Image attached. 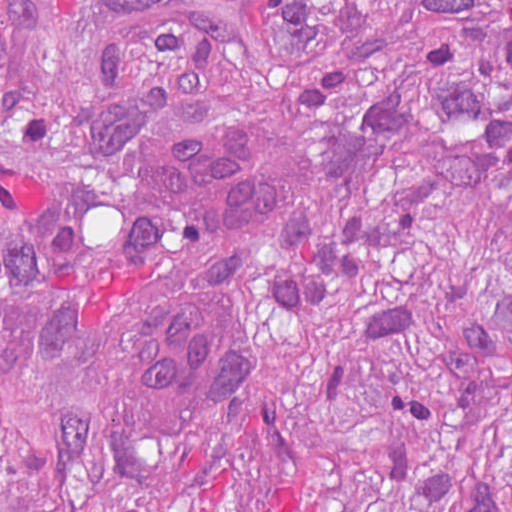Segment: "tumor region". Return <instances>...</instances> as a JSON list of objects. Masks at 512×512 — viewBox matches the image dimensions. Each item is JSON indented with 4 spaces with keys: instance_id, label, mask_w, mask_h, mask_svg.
<instances>
[{
    "instance_id": "tumor-region-1",
    "label": "tumor region",
    "mask_w": 512,
    "mask_h": 512,
    "mask_svg": "<svg viewBox=\"0 0 512 512\" xmlns=\"http://www.w3.org/2000/svg\"><path fill=\"white\" fill-rule=\"evenodd\" d=\"M247 114L277 224L194 243L161 151ZM245 331L221 413L129 356ZM1 512H512V0H1Z\"/></svg>"
}]
</instances>
